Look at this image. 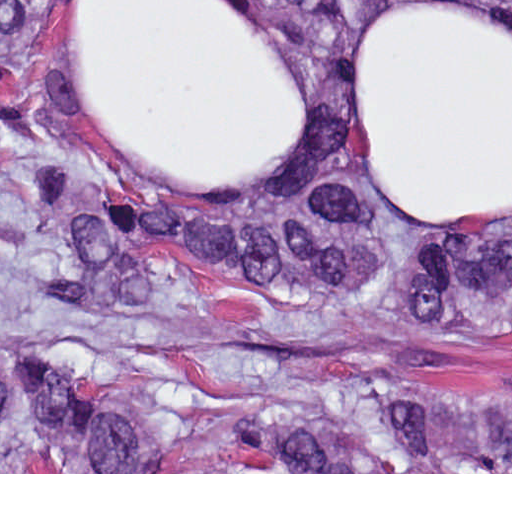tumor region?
<instances>
[{
	"mask_svg": "<svg viewBox=\"0 0 512 512\" xmlns=\"http://www.w3.org/2000/svg\"><path fill=\"white\" fill-rule=\"evenodd\" d=\"M56 0H1V140L37 152L56 118L45 74ZM367 0H278L326 91L322 182L246 214L170 209L71 188L36 166L29 205L63 245L44 292L112 312L151 295L152 260L223 283L343 300L388 254L345 170L339 48ZM382 318L512 329V223H432L405 251ZM1 472H512V394L372 378L268 389L224 415L150 433L50 354L1 355Z\"/></svg>",
	"mask_w": 512,
	"mask_h": 512,
	"instance_id": "1",
	"label": "tumor region"
}]
</instances>
